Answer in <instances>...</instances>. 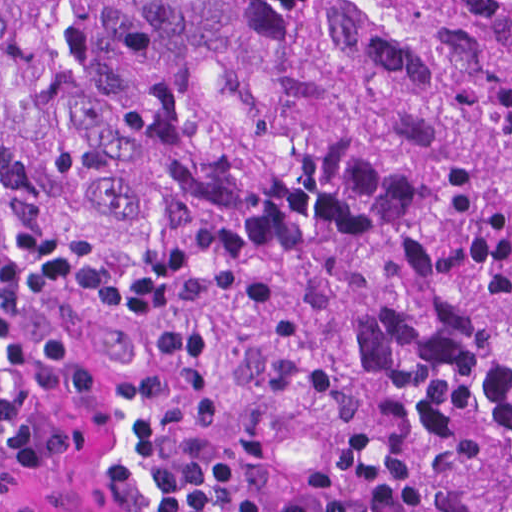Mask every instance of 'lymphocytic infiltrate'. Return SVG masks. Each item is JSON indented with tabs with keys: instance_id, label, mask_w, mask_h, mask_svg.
<instances>
[{
	"instance_id": "f902f5d3",
	"label": "lymphocytic infiltrate",
	"mask_w": 512,
	"mask_h": 512,
	"mask_svg": "<svg viewBox=\"0 0 512 512\" xmlns=\"http://www.w3.org/2000/svg\"><path fill=\"white\" fill-rule=\"evenodd\" d=\"M2 184L0 178V216ZM150 512H420L403 496L361 492L337 502L260 505L250 502L233 473L214 454L180 457L154 492Z\"/></svg>"
}]
</instances>
